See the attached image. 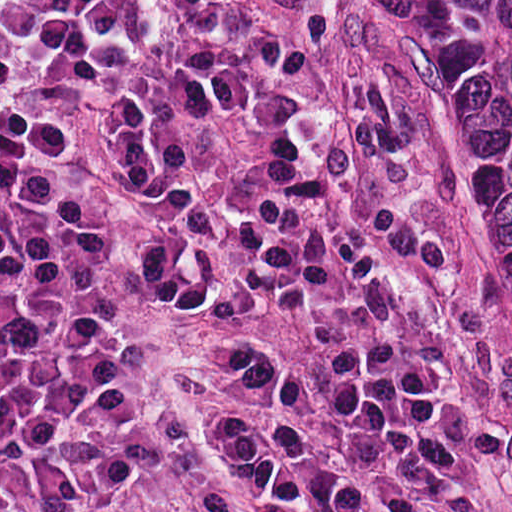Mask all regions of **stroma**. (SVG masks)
<instances>
[{
  "mask_svg": "<svg viewBox=\"0 0 512 512\" xmlns=\"http://www.w3.org/2000/svg\"><path fill=\"white\" fill-rule=\"evenodd\" d=\"M306 86L343 101L390 156L429 232L456 267L507 436L512 512V325L497 307L488 257L411 134L359 0H306Z\"/></svg>",
  "mask_w": 512,
  "mask_h": 512,
  "instance_id": "1",
  "label": "stroma"
}]
</instances>
